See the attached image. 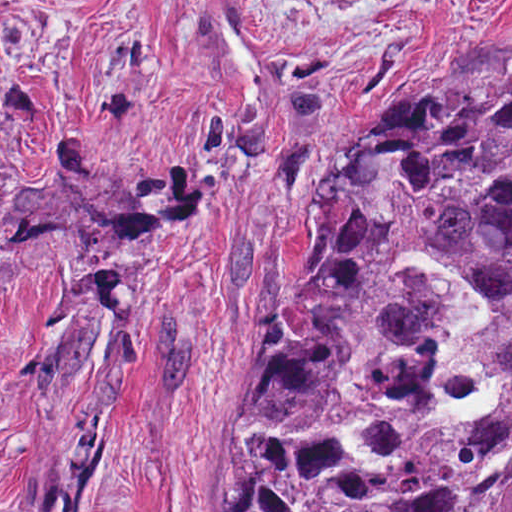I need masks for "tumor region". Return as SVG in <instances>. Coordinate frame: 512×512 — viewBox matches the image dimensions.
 <instances>
[{"mask_svg": "<svg viewBox=\"0 0 512 512\" xmlns=\"http://www.w3.org/2000/svg\"><path fill=\"white\" fill-rule=\"evenodd\" d=\"M315 258L271 306V370L227 512H512V401L429 425L454 316L421 253L491 308L449 368L512 374V79L383 85L315 165Z\"/></svg>", "mask_w": 512, "mask_h": 512, "instance_id": "obj_1", "label": "tumor region"}]
</instances>
